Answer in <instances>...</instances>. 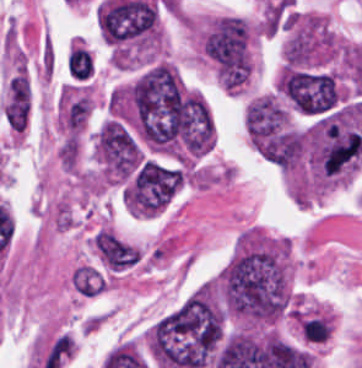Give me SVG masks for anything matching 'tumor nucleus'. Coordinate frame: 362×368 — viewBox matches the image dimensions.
<instances>
[{"label":"tumor nucleus","mask_w":362,"mask_h":368,"mask_svg":"<svg viewBox=\"0 0 362 368\" xmlns=\"http://www.w3.org/2000/svg\"><path fill=\"white\" fill-rule=\"evenodd\" d=\"M276 87L293 111L306 116H320L340 102L332 75L292 64L283 69Z\"/></svg>","instance_id":"1"}]
</instances>
